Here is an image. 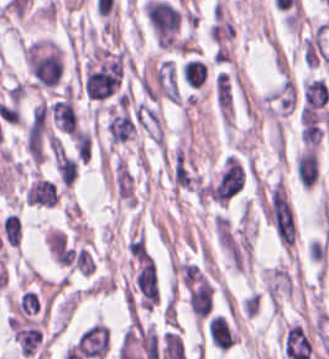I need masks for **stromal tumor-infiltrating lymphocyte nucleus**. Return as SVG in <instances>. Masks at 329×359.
I'll return each mask as SVG.
<instances>
[{"instance_id": "bc302bb0", "label": "stromal tumor-infiltrating lymphocyte nucleus", "mask_w": 329, "mask_h": 359, "mask_svg": "<svg viewBox=\"0 0 329 359\" xmlns=\"http://www.w3.org/2000/svg\"><path fill=\"white\" fill-rule=\"evenodd\" d=\"M75 347L88 359H103L109 349L107 325L94 323L77 336Z\"/></svg>"}, {"instance_id": "52c7bb5b", "label": "stromal tumor-infiltrating lymphocyte nucleus", "mask_w": 329, "mask_h": 359, "mask_svg": "<svg viewBox=\"0 0 329 359\" xmlns=\"http://www.w3.org/2000/svg\"><path fill=\"white\" fill-rule=\"evenodd\" d=\"M49 110L59 128L72 135L75 133L78 120L72 93L55 100Z\"/></svg>"}, {"instance_id": "3290ff9b", "label": "stromal tumor-infiltrating lymphocyte nucleus", "mask_w": 329, "mask_h": 359, "mask_svg": "<svg viewBox=\"0 0 329 359\" xmlns=\"http://www.w3.org/2000/svg\"><path fill=\"white\" fill-rule=\"evenodd\" d=\"M26 202L37 206H54L58 202L55 183L50 179L35 178L25 193Z\"/></svg>"}, {"instance_id": "abfb95fc", "label": "stromal tumor-infiltrating lymphocyte nucleus", "mask_w": 329, "mask_h": 359, "mask_svg": "<svg viewBox=\"0 0 329 359\" xmlns=\"http://www.w3.org/2000/svg\"><path fill=\"white\" fill-rule=\"evenodd\" d=\"M187 301L195 318L200 320L212 309L213 289L202 279L191 289Z\"/></svg>"}, {"instance_id": "9ea309e8", "label": "stromal tumor-infiltrating lymphocyte nucleus", "mask_w": 329, "mask_h": 359, "mask_svg": "<svg viewBox=\"0 0 329 359\" xmlns=\"http://www.w3.org/2000/svg\"><path fill=\"white\" fill-rule=\"evenodd\" d=\"M207 331L218 350H227L234 344V333L222 314H215Z\"/></svg>"}, {"instance_id": "f3e2335f", "label": "stromal tumor-infiltrating lymphocyte nucleus", "mask_w": 329, "mask_h": 359, "mask_svg": "<svg viewBox=\"0 0 329 359\" xmlns=\"http://www.w3.org/2000/svg\"><path fill=\"white\" fill-rule=\"evenodd\" d=\"M54 167L62 186L69 187L77 173L75 159L61 147L54 154Z\"/></svg>"}, {"instance_id": "4f13568d", "label": "stromal tumor-infiltrating lymphocyte nucleus", "mask_w": 329, "mask_h": 359, "mask_svg": "<svg viewBox=\"0 0 329 359\" xmlns=\"http://www.w3.org/2000/svg\"><path fill=\"white\" fill-rule=\"evenodd\" d=\"M181 73L187 86L198 88L205 83L207 65L202 60L194 57L181 65Z\"/></svg>"}, {"instance_id": "2a367800", "label": "stromal tumor-infiltrating lymphocyte nucleus", "mask_w": 329, "mask_h": 359, "mask_svg": "<svg viewBox=\"0 0 329 359\" xmlns=\"http://www.w3.org/2000/svg\"><path fill=\"white\" fill-rule=\"evenodd\" d=\"M0 226L1 232L8 245L17 248L20 242L21 227L16 214L11 212L9 215L3 217Z\"/></svg>"}, {"instance_id": "4803ca6d", "label": "stromal tumor-infiltrating lymphocyte nucleus", "mask_w": 329, "mask_h": 359, "mask_svg": "<svg viewBox=\"0 0 329 359\" xmlns=\"http://www.w3.org/2000/svg\"><path fill=\"white\" fill-rule=\"evenodd\" d=\"M73 148L77 159L86 164L91 155V134L86 128L77 129Z\"/></svg>"}, {"instance_id": "4245b91a", "label": "stromal tumor-infiltrating lymphocyte nucleus", "mask_w": 329, "mask_h": 359, "mask_svg": "<svg viewBox=\"0 0 329 359\" xmlns=\"http://www.w3.org/2000/svg\"><path fill=\"white\" fill-rule=\"evenodd\" d=\"M262 278H263V280H264V282H265V284H266V286H267V288H268V290L270 292V295H271V297H272V299H273V301H274V303H275V305L277 307V304H276V301H275V298H274V295H273L271 285H270V282H269V279H268V276H267L265 268H263V270H262ZM277 309H278V307H277Z\"/></svg>"}]
</instances>
